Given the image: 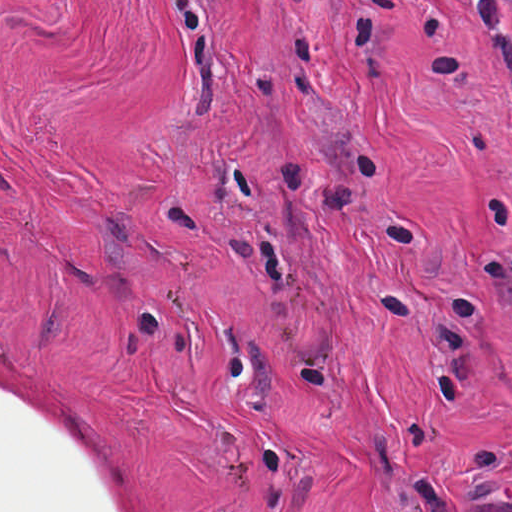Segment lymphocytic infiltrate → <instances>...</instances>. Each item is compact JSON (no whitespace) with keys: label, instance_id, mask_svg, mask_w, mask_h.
I'll return each mask as SVG.
<instances>
[{"label":"lymphocytic infiltrate","instance_id":"1","mask_svg":"<svg viewBox=\"0 0 512 512\" xmlns=\"http://www.w3.org/2000/svg\"><path fill=\"white\" fill-rule=\"evenodd\" d=\"M512 102V0H466Z\"/></svg>","mask_w":512,"mask_h":512}]
</instances>
